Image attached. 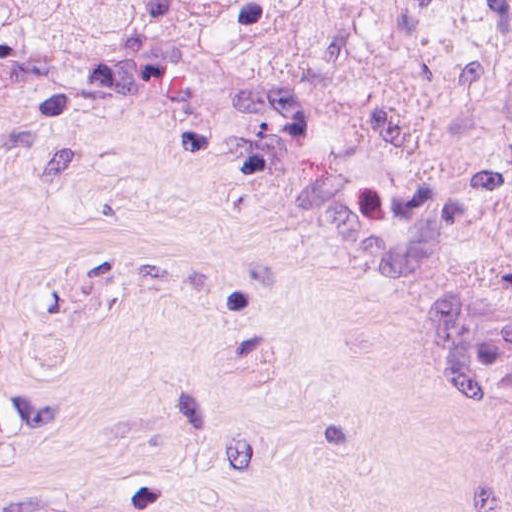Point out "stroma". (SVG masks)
<instances>
[{
  "label": "stroma",
  "mask_w": 512,
  "mask_h": 512,
  "mask_svg": "<svg viewBox=\"0 0 512 512\" xmlns=\"http://www.w3.org/2000/svg\"><path fill=\"white\" fill-rule=\"evenodd\" d=\"M0 512H512V321L82 107L0 240Z\"/></svg>",
  "instance_id": "obj_1"
}]
</instances>
